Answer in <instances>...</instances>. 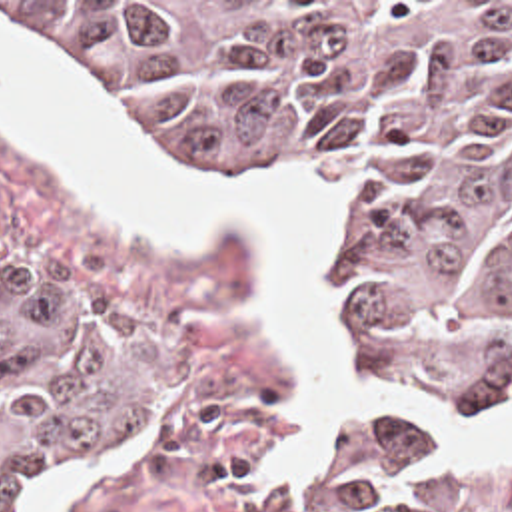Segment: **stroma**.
Here are the masks:
<instances>
[{"instance_id": "1", "label": "stroma", "mask_w": 512, "mask_h": 512, "mask_svg": "<svg viewBox=\"0 0 512 512\" xmlns=\"http://www.w3.org/2000/svg\"><path fill=\"white\" fill-rule=\"evenodd\" d=\"M0 12L37 32L25 20L1 8ZM65 54L101 86L122 120L134 124L192 176L314 174L334 182L342 192V236L328 254V276L340 297L350 365L368 381L390 385L450 417L512 413V399H450L406 381L346 319L360 276V204L350 176L334 160L246 164L218 156L168 128L144 110L124 86L104 80L73 54ZM0 258L69 291L128 345L148 357V383L134 411L87 447L95 449L130 433L136 427L130 421H146L140 451L122 461L112 475L75 485L67 497V512H276L320 437L348 421L312 423L288 477L274 485L260 481L268 459L288 439L286 401L294 393L296 379L274 337L250 327L244 317V303L262 280L256 250L236 236L202 250L138 246L106 222L89 192L43 156L19 146L1 126ZM380 415H406L430 429L416 413ZM55 471H39L17 485L11 512H25L33 489ZM436 512H512V471H458L446 463V489Z\"/></svg>"}]
</instances>
